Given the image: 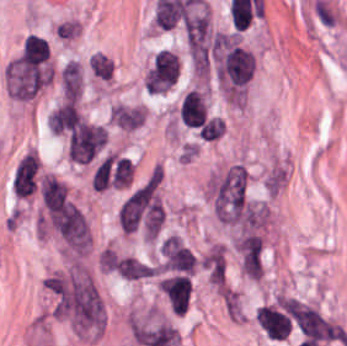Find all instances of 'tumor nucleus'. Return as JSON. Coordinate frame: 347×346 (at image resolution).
<instances>
[{
	"label": "tumor nucleus",
	"mask_w": 347,
	"mask_h": 346,
	"mask_svg": "<svg viewBox=\"0 0 347 346\" xmlns=\"http://www.w3.org/2000/svg\"><path fill=\"white\" fill-rule=\"evenodd\" d=\"M64 96L67 100L78 101L82 91V79L79 64L69 61L61 73Z\"/></svg>",
	"instance_id": "tumor-nucleus-1"
}]
</instances>
